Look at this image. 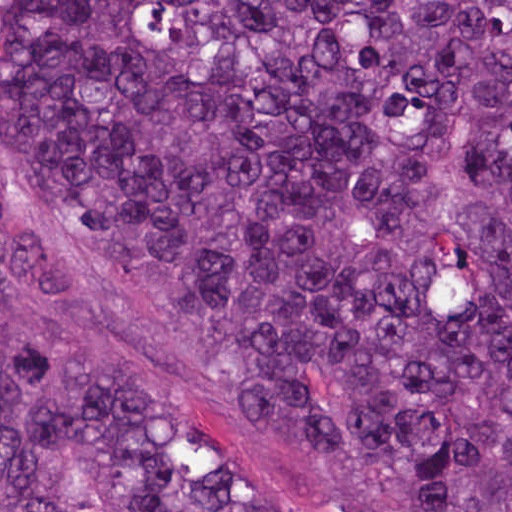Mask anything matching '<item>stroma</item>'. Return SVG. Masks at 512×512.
Wrapping results in <instances>:
<instances>
[{
	"label": "stroma",
	"instance_id": "35a3bbf8",
	"mask_svg": "<svg viewBox=\"0 0 512 512\" xmlns=\"http://www.w3.org/2000/svg\"><path fill=\"white\" fill-rule=\"evenodd\" d=\"M0 331L49 343L148 417L215 450L297 512L278 460L212 383L172 364L119 311L87 245L0 145Z\"/></svg>",
	"mask_w": 512,
	"mask_h": 512
}]
</instances>
